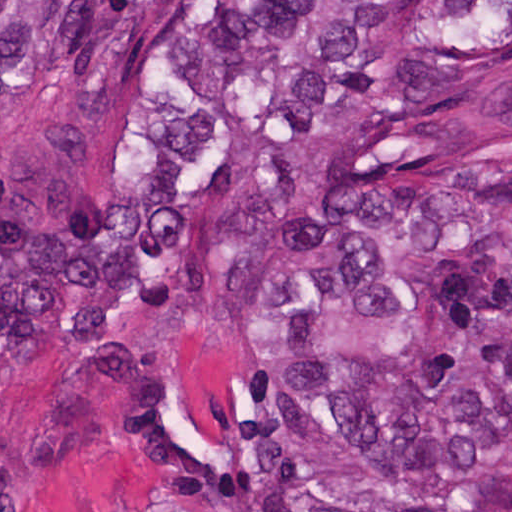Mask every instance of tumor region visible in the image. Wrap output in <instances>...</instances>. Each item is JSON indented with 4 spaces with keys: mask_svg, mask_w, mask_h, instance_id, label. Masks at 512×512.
<instances>
[{
    "mask_svg": "<svg viewBox=\"0 0 512 512\" xmlns=\"http://www.w3.org/2000/svg\"><path fill=\"white\" fill-rule=\"evenodd\" d=\"M182 1H0V92L135 74ZM225 1L180 31L135 162L61 167L0 210V349L62 331L203 473L151 321L312 197L248 275L257 318L381 310V352L286 365L246 480L205 512H512V1ZM314 149L310 154L311 147Z\"/></svg>",
    "mask_w": 512,
    "mask_h": 512,
    "instance_id": "e687c5a6",
    "label": "tumor region"
}]
</instances>
